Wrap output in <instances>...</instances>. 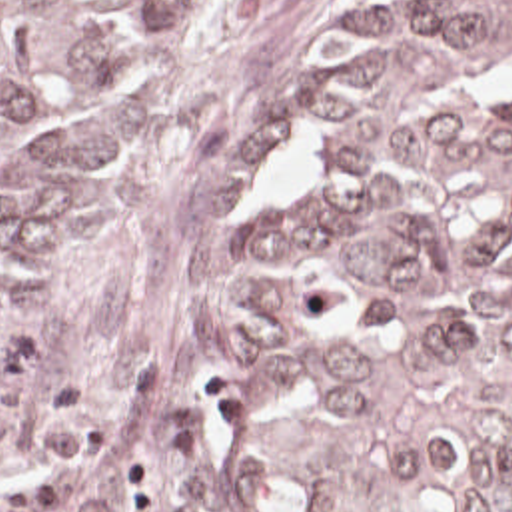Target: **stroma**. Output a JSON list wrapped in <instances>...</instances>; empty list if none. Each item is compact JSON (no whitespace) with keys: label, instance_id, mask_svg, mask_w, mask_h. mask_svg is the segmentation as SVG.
I'll return each instance as SVG.
<instances>
[{"label":"stroma","instance_id":"1","mask_svg":"<svg viewBox=\"0 0 512 512\" xmlns=\"http://www.w3.org/2000/svg\"><path fill=\"white\" fill-rule=\"evenodd\" d=\"M355 0H251L133 132L69 250L31 292L0 294V512H73L25 454L33 396L65 378L99 430L89 476L153 452L163 512H273L223 394L259 212L307 162L301 56Z\"/></svg>","mask_w":512,"mask_h":512}]
</instances>
